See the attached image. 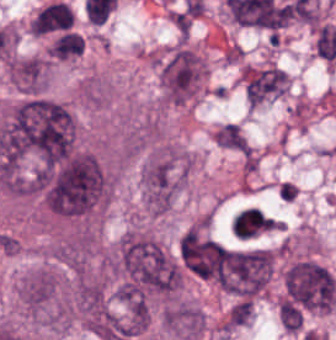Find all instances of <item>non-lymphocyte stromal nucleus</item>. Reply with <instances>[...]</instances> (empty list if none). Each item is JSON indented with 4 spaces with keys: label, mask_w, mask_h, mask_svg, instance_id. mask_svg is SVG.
Masks as SVG:
<instances>
[{
    "label": "non-lymphocyte stromal nucleus",
    "mask_w": 336,
    "mask_h": 340,
    "mask_svg": "<svg viewBox=\"0 0 336 340\" xmlns=\"http://www.w3.org/2000/svg\"><path fill=\"white\" fill-rule=\"evenodd\" d=\"M72 12L64 2L53 1L37 10L29 28L34 34H46L69 28Z\"/></svg>",
    "instance_id": "1"
},
{
    "label": "non-lymphocyte stromal nucleus",
    "mask_w": 336,
    "mask_h": 340,
    "mask_svg": "<svg viewBox=\"0 0 336 340\" xmlns=\"http://www.w3.org/2000/svg\"><path fill=\"white\" fill-rule=\"evenodd\" d=\"M83 52L82 35L65 31L49 47V55L60 60H67Z\"/></svg>",
    "instance_id": "2"
}]
</instances>
